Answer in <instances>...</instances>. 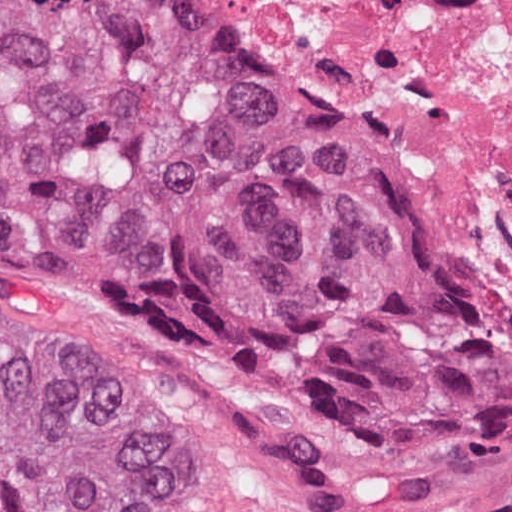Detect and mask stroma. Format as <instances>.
Instances as JSON below:
<instances>
[{"label":"stroma","instance_id":"obj_1","mask_svg":"<svg viewBox=\"0 0 512 512\" xmlns=\"http://www.w3.org/2000/svg\"><path fill=\"white\" fill-rule=\"evenodd\" d=\"M203 1L270 47L220 0ZM337 112L434 235L407 179ZM0 304L80 343L158 416L172 512H512V465L410 439L221 330L2 248Z\"/></svg>","mask_w":512,"mask_h":512}]
</instances>
